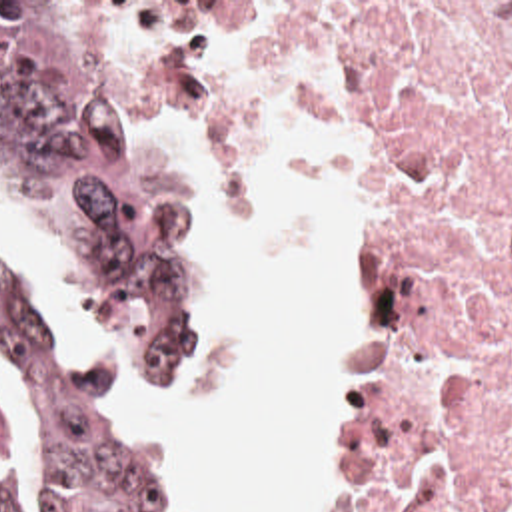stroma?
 Wrapping results in <instances>:
<instances>
[{
  "mask_svg": "<svg viewBox=\"0 0 512 512\" xmlns=\"http://www.w3.org/2000/svg\"><path fill=\"white\" fill-rule=\"evenodd\" d=\"M0 2H96L106 58L118 102L138 118L182 166L194 186L202 216V331L210 319L224 268V220L220 204L162 114L212 126L226 138L314 144L330 168L332 186L346 216V379L342 383V429L322 512H372L382 465V411L390 383V335L382 311L370 240V150L340 124L318 122L280 96L240 82L196 76L164 56L160 2H512V0H0ZM18 198L26 220L56 272L78 299V343L68 353L94 373L118 411L134 421L174 497L178 512H202L176 455L148 427L160 415L186 407L196 373L164 401H122L110 385L98 349L94 313L76 274L54 242L32 200L0 178ZM0 256L30 281L28 262L0 244ZM44 303V301H42ZM66 351V349H62ZM200 367V363H198Z\"/></svg>",
  "mask_w": 512,
  "mask_h": 512,
  "instance_id": "stroma-1",
  "label": "stroma"
}]
</instances>
